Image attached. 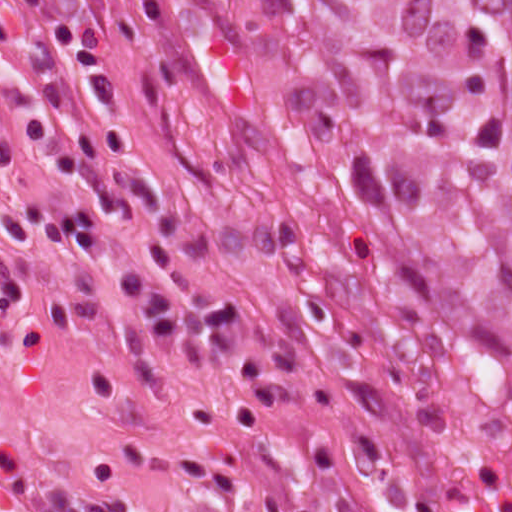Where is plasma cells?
I'll return each mask as SVG.
<instances>
[{"label": "plasma cells", "mask_w": 512, "mask_h": 512, "mask_svg": "<svg viewBox=\"0 0 512 512\" xmlns=\"http://www.w3.org/2000/svg\"><path fill=\"white\" fill-rule=\"evenodd\" d=\"M3 1L22 12H33L43 0ZM17 167L14 140L0 122V172L10 176ZM138 203L165 211L169 195L153 178L120 163L95 181L71 210L23 200L4 211L0 216V314L19 311L32 297L31 283L15 262V253L68 246L84 261L100 258L110 242L98 210L123 222ZM173 286L136 268H125L117 278L119 292L140 319L155 351L170 354L186 339L219 356H229L241 346L245 300L210 289L185 269L175 270Z\"/></svg>", "instance_id": "9512152a"}]
</instances>
